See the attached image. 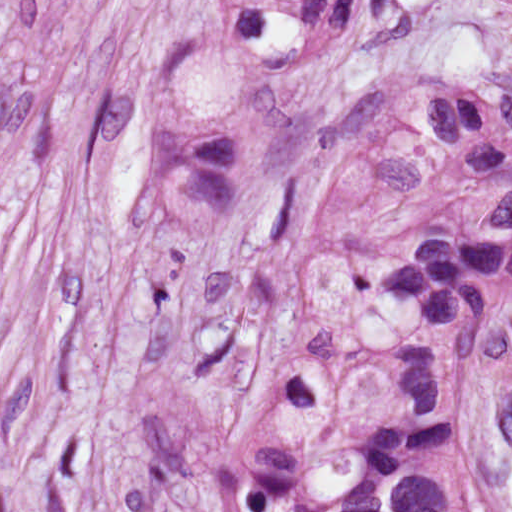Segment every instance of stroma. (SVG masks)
Returning a JSON list of instances; mask_svg holds the SVG:
<instances>
[{"label": "stroma", "mask_w": 512, "mask_h": 512, "mask_svg": "<svg viewBox=\"0 0 512 512\" xmlns=\"http://www.w3.org/2000/svg\"><path fill=\"white\" fill-rule=\"evenodd\" d=\"M212 0H0V512H96L118 417L173 389L250 425L388 385L399 325L311 300L310 243L358 158L343 113L388 83L512 93V3L362 0L297 98L256 208L214 246L143 215L154 96ZM512 512V311L467 419ZM159 512H212L199 493Z\"/></svg>", "instance_id": "stroma-1"}]
</instances>
